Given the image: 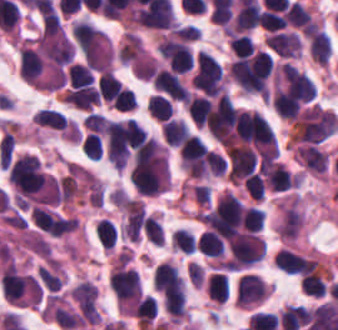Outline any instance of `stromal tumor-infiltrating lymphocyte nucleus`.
Listing matches in <instances>:
<instances>
[{
  "label": "stromal tumor-infiltrating lymphocyte nucleus",
  "mask_w": 338,
  "mask_h": 330,
  "mask_svg": "<svg viewBox=\"0 0 338 330\" xmlns=\"http://www.w3.org/2000/svg\"><path fill=\"white\" fill-rule=\"evenodd\" d=\"M64 100L81 109H90L97 102V87L86 66L71 64Z\"/></svg>",
  "instance_id": "bc302bb0"
},
{
  "label": "stromal tumor-infiltrating lymphocyte nucleus",
  "mask_w": 338,
  "mask_h": 330,
  "mask_svg": "<svg viewBox=\"0 0 338 330\" xmlns=\"http://www.w3.org/2000/svg\"><path fill=\"white\" fill-rule=\"evenodd\" d=\"M318 261L296 253L294 251L279 248L274 255V267L284 273L306 274L314 271Z\"/></svg>",
  "instance_id": "52c7bb5b"
},
{
  "label": "stromal tumor-infiltrating lymphocyte nucleus",
  "mask_w": 338,
  "mask_h": 330,
  "mask_svg": "<svg viewBox=\"0 0 338 330\" xmlns=\"http://www.w3.org/2000/svg\"><path fill=\"white\" fill-rule=\"evenodd\" d=\"M266 285L259 277L244 274L239 277L237 286V301L240 307H250L265 298Z\"/></svg>",
  "instance_id": "3290ff9b"
},
{
  "label": "stromal tumor-infiltrating lymphocyte nucleus",
  "mask_w": 338,
  "mask_h": 330,
  "mask_svg": "<svg viewBox=\"0 0 338 330\" xmlns=\"http://www.w3.org/2000/svg\"><path fill=\"white\" fill-rule=\"evenodd\" d=\"M263 184L274 192L285 191L293 187V181L279 162H272L260 171Z\"/></svg>",
  "instance_id": "abfb95fc"
},
{
  "label": "stromal tumor-infiltrating lymphocyte nucleus",
  "mask_w": 338,
  "mask_h": 330,
  "mask_svg": "<svg viewBox=\"0 0 338 330\" xmlns=\"http://www.w3.org/2000/svg\"><path fill=\"white\" fill-rule=\"evenodd\" d=\"M161 136L167 146H180L188 136L183 118L168 117L160 124Z\"/></svg>",
  "instance_id": "9ea309e8"
},
{
  "label": "stromal tumor-infiltrating lymphocyte nucleus",
  "mask_w": 338,
  "mask_h": 330,
  "mask_svg": "<svg viewBox=\"0 0 338 330\" xmlns=\"http://www.w3.org/2000/svg\"><path fill=\"white\" fill-rule=\"evenodd\" d=\"M285 23L296 30L308 33L314 25L309 11L296 2H289L284 13Z\"/></svg>",
  "instance_id": "f3e2335f"
},
{
  "label": "stromal tumor-infiltrating lymphocyte nucleus",
  "mask_w": 338,
  "mask_h": 330,
  "mask_svg": "<svg viewBox=\"0 0 338 330\" xmlns=\"http://www.w3.org/2000/svg\"><path fill=\"white\" fill-rule=\"evenodd\" d=\"M211 102L200 94L190 95L185 102V109L194 126L202 127L209 117Z\"/></svg>",
  "instance_id": "4f13568d"
},
{
  "label": "stromal tumor-infiltrating lymphocyte nucleus",
  "mask_w": 338,
  "mask_h": 330,
  "mask_svg": "<svg viewBox=\"0 0 338 330\" xmlns=\"http://www.w3.org/2000/svg\"><path fill=\"white\" fill-rule=\"evenodd\" d=\"M308 53L316 64L325 67L330 55L327 34L316 28L308 38Z\"/></svg>",
  "instance_id": "2a367800"
},
{
  "label": "stromal tumor-infiltrating lymphocyte nucleus",
  "mask_w": 338,
  "mask_h": 330,
  "mask_svg": "<svg viewBox=\"0 0 338 330\" xmlns=\"http://www.w3.org/2000/svg\"><path fill=\"white\" fill-rule=\"evenodd\" d=\"M195 247L203 255L213 258H221L224 253L223 243L214 232L203 231L195 241Z\"/></svg>",
  "instance_id": "4803ca6d"
},
{
  "label": "stromal tumor-infiltrating lymphocyte nucleus",
  "mask_w": 338,
  "mask_h": 330,
  "mask_svg": "<svg viewBox=\"0 0 338 330\" xmlns=\"http://www.w3.org/2000/svg\"><path fill=\"white\" fill-rule=\"evenodd\" d=\"M205 291L214 302L224 303L229 296L228 275L213 272L207 281Z\"/></svg>",
  "instance_id": "4245b91a"
},
{
  "label": "stromal tumor-infiltrating lymphocyte nucleus",
  "mask_w": 338,
  "mask_h": 330,
  "mask_svg": "<svg viewBox=\"0 0 338 330\" xmlns=\"http://www.w3.org/2000/svg\"><path fill=\"white\" fill-rule=\"evenodd\" d=\"M146 111L155 121L162 122L170 117L173 109L169 98L159 93H151L146 101Z\"/></svg>",
  "instance_id": "4c9ddf68"
},
{
  "label": "stromal tumor-infiltrating lymphocyte nucleus",
  "mask_w": 338,
  "mask_h": 330,
  "mask_svg": "<svg viewBox=\"0 0 338 330\" xmlns=\"http://www.w3.org/2000/svg\"><path fill=\"white\" fill-rule=\"evenodd\" d=\"M32 121L39 126L61 129L67 122L66 117L61 112L49 107H41L35 111Z\"/></svg>",
  "instance_id": "2761f720"
},
{
  "label": "stromal tumor-infiltrating lymphocyte nucleus",
  "mask_w": 338,
  "mask_h": 330,
  "mask_svg": "<svg viewBox=\"0 0 338 330\" xmlns=\"http://www.w3.org/2000/svg\"><path fill=\"white\" fill-rule=\"evenodd\" d=\"M240 222L248 233H258L264 226L263 211L254 206H247L242 212Z\"/></svg>",
  "instance_id": "3c572f05"
},
{
  "label": "stromal tumor-infiltrating lymphocyte nucleus",
  "mask_w": 338,
  "mask_h": 330,
  "mask_svg": "<svg viewBox=\"0 0 338 330\" xmlns=\"http://www.w3.org/2000/svg\"><path fill=\"white\" fill-rule=\"evenodd\" d=\"M94 234L100 246L105 250H112L116 231L109 221L101 218L94 227Z\"/></svg>",
  "instance_id": "42bb06b2"
},
{
  "label": "stromal tumor-infiltrating lymphocyte nucleus",
  "mask_w": 338,
  "mask_h": 330,
  "mask_svg": "<svg viewBox=\"0 0 338 330\" xmlns=\"http://www.w3.org/2000/svg\"><path fill=\"white\" fill-rule=\"evenodd\" d=\"M299 287L312 296L322 297L325 292L324 282L315 270L299 277Z\"/></svg>",
  "instance_id": "9e4306bb"
},
{
  "label": "stromal tumor-infiltrating lymphocyte nucleus",
  "mask_w": 338,
  "mask_h": 330,
  "mask_svg": "<svg viewBox=\"0 0 338 330\" xmlns=\"http://www.w3.org/2000/svg\"><path fill=\"white\" fill-rule=\"evenodd\" d=\"M173 250L192 254L194 252L193 235L184 228H177L170 234Z\"/></svg>",
  "instance_id": "04cf8593"
},
{
  "label": "stromal tumor-infiltrating lymphocyte nucleus",
  "mask_w": 338,
  "mask_h": 330,
  "mask_svg": "<svg viewBox=\"0 0 338 330\" xmlns=\"http://www.w3.org/2000/svg\"><path fill=\"white\" fill-rule=\"evenodd\" d=\"M141 229L149 242L161 246L164 234L155 216L145 215Z\"/></svg>",
  "instance_id": "e9af9c67"
},
{
  "label": "stromal tumor-infiltrating lymphocyte nucleus",
  "mask_w": 338,
  "mask_h": 330,
  "mask_svg": "<svg viewBox=\"0 0 338 330\" xmlns=\"http://www.w3.org/2000/svg\"><path fill=\"white\" fill-rule=\"evenodd\" d=\"M229 47L240 58L253 54L255 49L251 38L246 34H233L229 39Z\"/></svg>",
  "instance_id": "782c7336"
},
{
  "label": "stromal tumor-infiltrating lymphocyte nucleus",
  "mask_w": 338,
  "mask_h": 330,
  "mask_svg": "<svg viewBox=\"0 0 338 330\" xmlns=\"http://www.w3.org/2000/svg\"><path fill=\"white\" fill-rule=\"evenodd\" d=\"M242 183L249 198L259 202L262 200L264 185L261 176L254 172L244 179Z\"/></svg>",
  "instance_id": "cac63f63"
},
{
  "label": "stromal tumor-infiltrating lymphocyte nucleus",
  "mask_w": 338,
  "mask_h": 330,
  "mask_svg": "<svg viewBox=\"0 0 338 330\" xmlns=\"http://www.w3.org/2000/svg\"><path fill=\"white\" fill-rule=\"evenodd\" d=\"M204 162L208 173L214 176H221L226 160L214 150H207L204 155Z\"/></svg>",
  "instance_id": "2e467ee5"
}]
</instances>
